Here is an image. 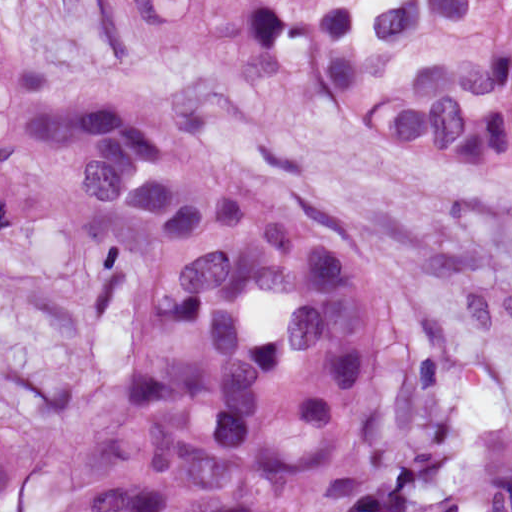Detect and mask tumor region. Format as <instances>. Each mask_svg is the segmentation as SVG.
Returning <instances> with one entry per match:
<instances>
[{
	"label": "tumor region",
	"instance_id": "obj_1",
	"mask_svg": "<svg viewBox=\"0 0 512 512\" xmlns=\"http://www.w3.org/2000/svg\"><path fill=\"white\" fill-rule=\"evenodd\" d=\"M115 102L0 7V266L122 356L60 512H512V420L409 453L391 310L335 235L185 125L306 110L512 201V0H85ZM24 487L0 440V505Z\"/></svg>",
	"mask_w": 512,
	"mask_h": 512
}]
</instances>
